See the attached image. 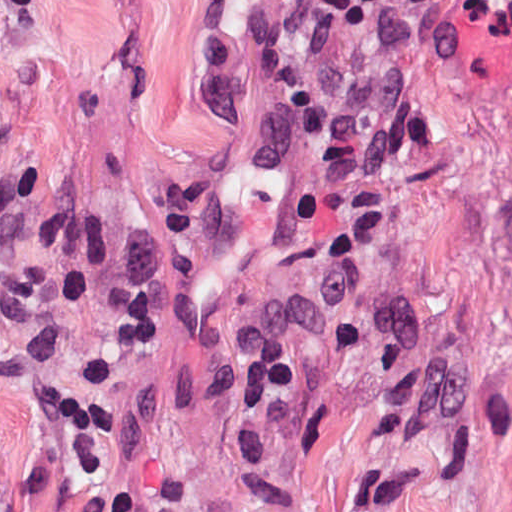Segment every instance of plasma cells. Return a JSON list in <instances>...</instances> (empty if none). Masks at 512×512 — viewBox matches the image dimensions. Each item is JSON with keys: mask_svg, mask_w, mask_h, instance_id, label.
<instances>
[{"mask_svg": "<svg viewBox=\"0 0 512 512\" xmlns=\"http://www.w3.org/2000/svg\"><path fill=\"white\" fill-rule=\"evenodd\" d=\"M0 110V389L24 396L38 460L18 491L33 512H183L174 470L138 485L116 469L127 429L97 351L72 373L71 307L109 311L128 349L170 320L208 401L256 480L284 432L318 350L352 315L373 352L370 423L395 436L463 411L462 388L436 327L392 268L394 216L381 193L347 196L346 228L328 284L313 301L261 314L250 330L214 315L204 281L235 223V164L194 166L146 200L153 230L137 235L80 218L63 185L10 165Z\"/></svg>", "mask_w": 512, "mask_h": 512, "instance_id": "1", "label": "plasma cells"}]
</instances>
